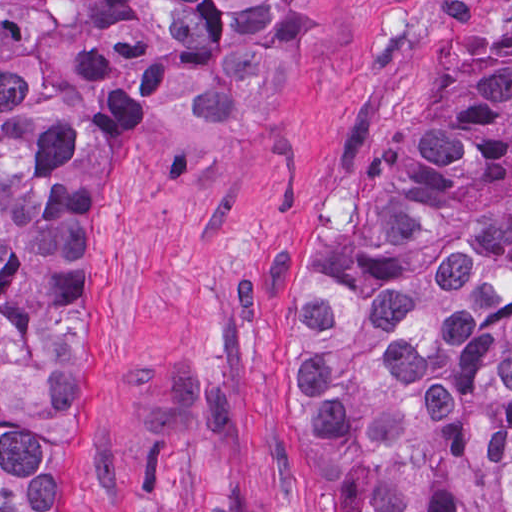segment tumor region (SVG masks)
I'll return each instance as SVG.
<instances>
[{
	"label": "tumor region",
	"instance_id": "obj_1",
	"mask_svg": "<svg viewBox=\"0 0 512 512\" xmlns=\"http://www.w3.org/2000/svg\"><path fill=\"white\" fill-rule=\"evenodd\" d=\"M299 1H0V512H71L75 219L108 128L241 127ZM298 425L324 512H512V64L435 97L311 274Z\"/></svg>",
	"mask_w": 512,
	"mask_h": 512
}]
</instances>
